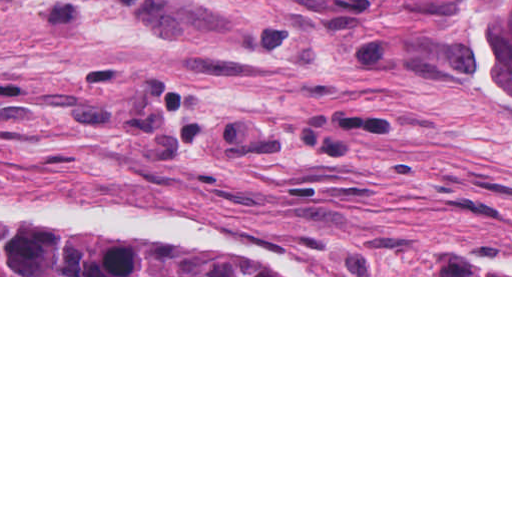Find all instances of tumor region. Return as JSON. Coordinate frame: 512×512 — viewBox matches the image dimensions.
<instances>
[{
    "label": "tumor region",
    "mask_w": 512,
    "mask_h": 512,
    "mask_svg": "<svg viewBox=\"0 0 512 512\" xmlns=\"http://www.w3.org/2000/svg\"><path fill=\"white\" fill-rule=\"evenodd\" d=\"M478 60L512 93V0H458ZM0 275H293L281 252L208 253L143 243L115 224L0 229Z\"/></svg>",
    "instance_id": "e687c5a6"
}]
</instances>
